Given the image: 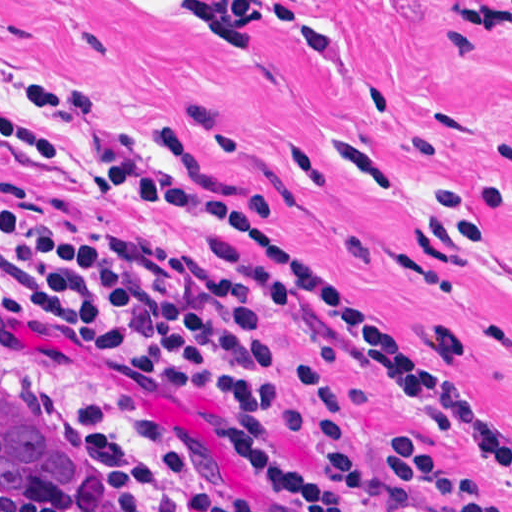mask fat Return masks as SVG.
<instances>
[{
    "instance_id": "fat-1",
    "label": "fat",
    "mask_w": 512,
    "mask_h": 512,
    "mask_svg": "<svg viewBox=\"0 0 512 512\" xmlns=\"http://www.w3.org/2000/svg\"><path fill=\"white\" fill-rule=\"evenodd\" d=\"M133 23H173L195 14V0H106Z\"/></svg>"
}]
</instances>
